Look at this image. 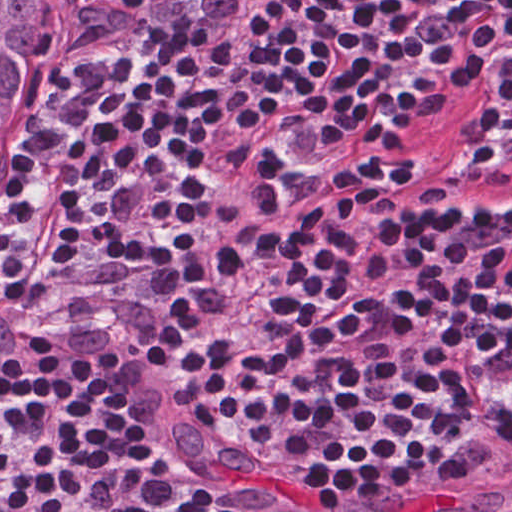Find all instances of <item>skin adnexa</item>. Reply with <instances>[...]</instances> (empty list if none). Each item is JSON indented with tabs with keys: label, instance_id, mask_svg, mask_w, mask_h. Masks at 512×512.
Wrapping results in <instances>:
<instances>
[{
	"label": "skin adnexa",
	"instance_id": "bc48264e",
	"mask_svg": "<svg viewBox=\"0 0 512 512\" xmlns=\"http://www.w3.org/2000/svg\"><path fill=\"white\" fill-rule=\"evenodd\" d=\"M65 5L66 0H0V147L23 94L47 67Z\"/></svg>",
	"mask_w": 512,
	"mask_h": 512
}]
</instances>
